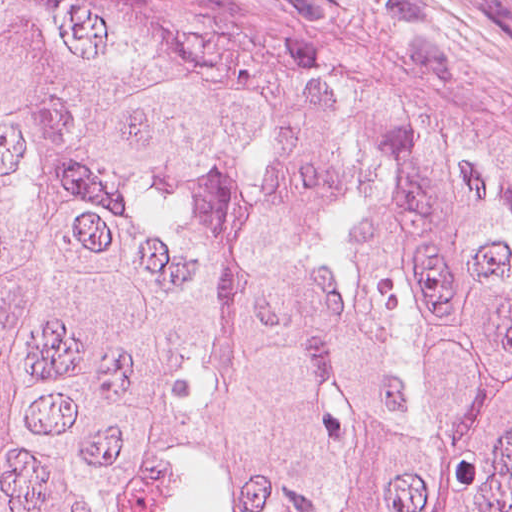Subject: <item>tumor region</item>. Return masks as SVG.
I'll list each match as a JSON object with an SVG mask.
<instances>
[{"label":"tumor region","instance_id":"e687c5a6","mask_svg":"<svg viewBox=\"0 0 512 512\" xmlns=\"http://www.w3.org/2000/svg\"><path fill=\"white\" fill-rule=\"evenodd\" d=\"M0 512H512V134L0 0Z\"/></svg>","mask_w":512,"mask_h":512}]
</instances>
